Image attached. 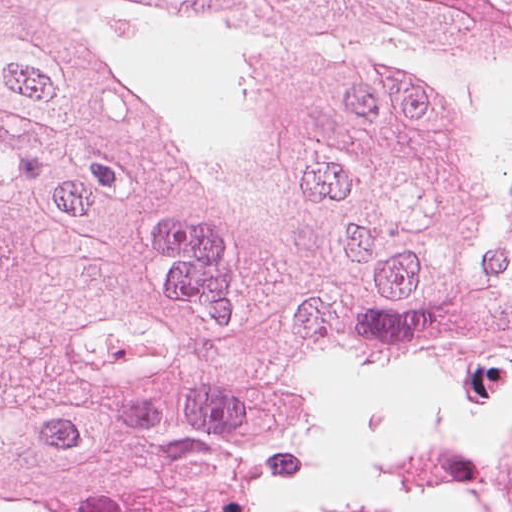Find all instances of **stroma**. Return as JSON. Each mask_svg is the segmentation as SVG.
Segmentation results:
<instances>
[{
  "label": "stroma",
  "mask_w": 512,
  "mask_h": 512,
  "mask_svg": "<svg viewBox=\"0 0 512 512\" xmlns=\"http://www.w3.org/2000/svg\"><path fill=\"white\" fill-rule=\"evenodd\" d=\"M484 373L340 368L308 455L254 512L410 495L457 508Z\"/></svg>",
  "instance_id": "stroma-1"
}]
</instances>
